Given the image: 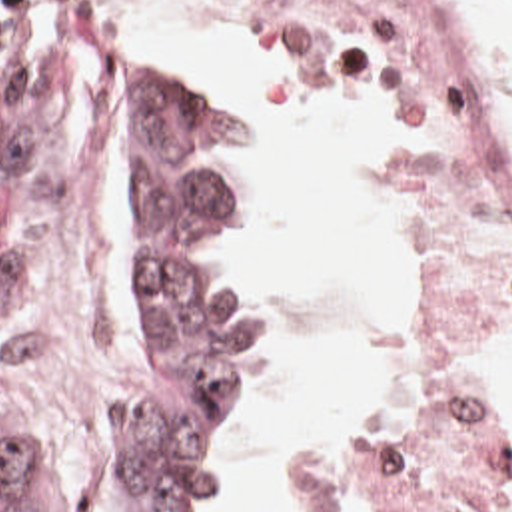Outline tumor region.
<instances>
[{
	"mask_svg": "<svg viewBox=\"0 0 512 512\" xmlns=\"http://www.w3.org/2000/svg\"><path fill=\"white\" fill-rule=\"evenodd\" d=\"M59 14L81 32L141 38L105 12ZM63 122L41 88L0 74V374L31 352L33 192ZM107 148L139 208V320L111 395L107 463L139 509L97 512H213L259 387V342L247 316L207 298L197 276L231 258L257 216V140L231 102L167 58L143 78L135 142ZM0 512H61L3 413Z\"/></svg>",
	"mask_w": 512,
	"mask_h": 512,
	"instance_id": "tumor-region-1",
	"label": "tumor region"
}]
</instances>
